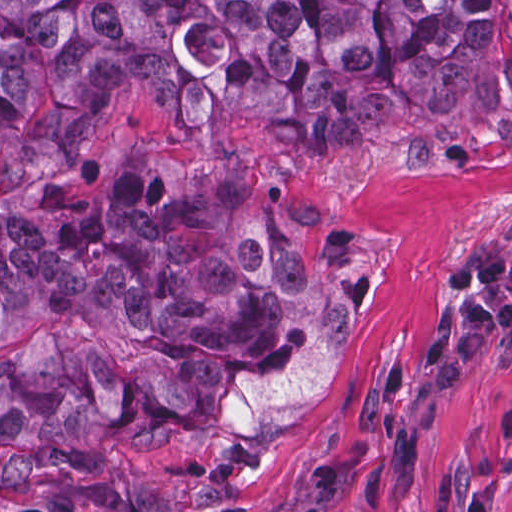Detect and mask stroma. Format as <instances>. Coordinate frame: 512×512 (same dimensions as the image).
I'll use <instances>...</instances> for the list:
<instances>
[{"label": "stroma", "instance_id": "35a3bbf8", "mask_svg": "<svg viewBox=\"0 0 512 512\" xmlns=\"http://www.w3.org/2000/svg\"><path fill=\"white\" fill-rule=\"evenodd\" d=\"M323 214L369 241L364 284L329 382L297 433L240 483L162 495L0 456V512H300L315 461L346 468L332 512H512V334L456 385L424 360L443 309L463 299L445 275L466 249L512 254V155L460 177L403 174L357 157L282 153Z\"/></svg>", "mask_w": 512, "mask_h": 512}]
</instances>
